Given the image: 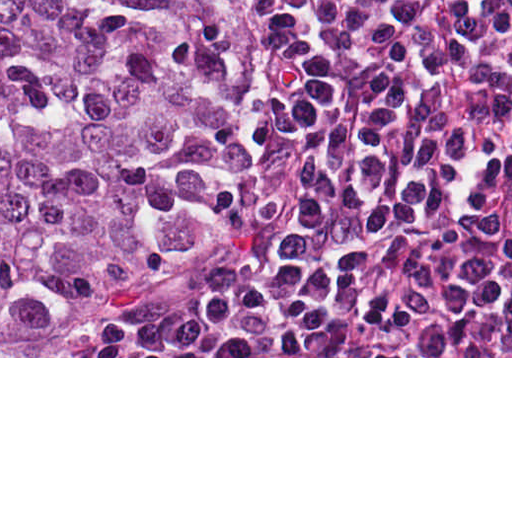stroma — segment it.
<instances>
[{
    "label": "stroma",
    "mask_w": 512,
    "mask_h": 512,
    "mask_svg": "<svg viewBox=\"0 0 512 512\" xmlns=\"http://www.w3.org/2000/svg\"><path fill=\"white\" fill-rule=\"evenodd\" d=\"M257 19L274 43L278 56L273 72L253 91L260 114L287 134L298 147L307 176L286 249L241 260L237 267L221 269L207 279L165 298L136 317L115 356H0V358H512V356H123L132 347L210 309L239 302L268 287L288 273L298 260L310 212L321 189V170L302 130L276 104L287 61L252 0H237Z\"/></svg>",
    "instance_id": "stroma-1"
}]
</instances>
